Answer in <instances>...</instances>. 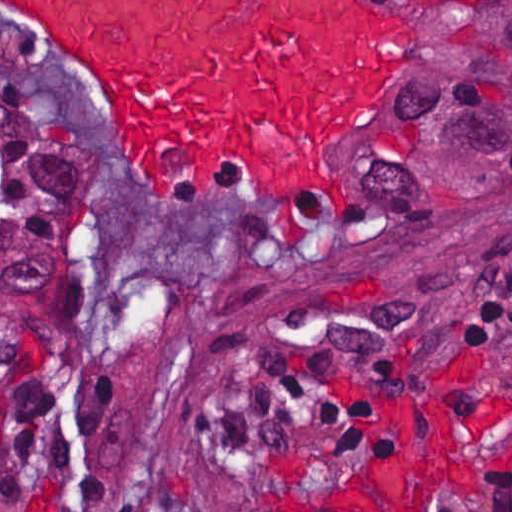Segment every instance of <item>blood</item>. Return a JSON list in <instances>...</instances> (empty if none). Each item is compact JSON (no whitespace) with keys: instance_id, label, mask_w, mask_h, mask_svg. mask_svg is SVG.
<instances>
[{"instance_id":"blood-1","label":"blood","mask_w":512,"mask_h":512,"mask_svg":"<svg viewBox=\"0 0 512 512\" xmlns=\"http://www.w3.org/2000/svg\"><path fill=\"white\" fill-rule=\"evenodd\" d=\"M54 48L135 179L190 211L261 204L284 235L337 225L347 133L381 94L398 23L383 0H0ZM443 395L405 469L241 512H432L456 466Z\"/></svg>"}]
</instances>
